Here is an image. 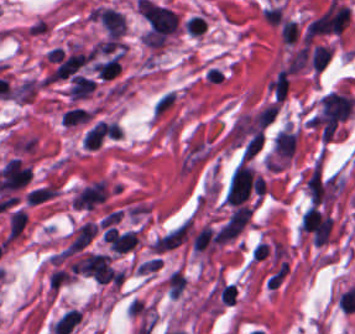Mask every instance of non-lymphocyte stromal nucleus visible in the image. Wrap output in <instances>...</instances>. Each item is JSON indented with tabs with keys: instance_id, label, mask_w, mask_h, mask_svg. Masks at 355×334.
<instances>
[{
	"instance_id": "dd21d789",
	"label": "non-lymphocyte stromal nucleus",
	"mask_w": 355,
	"mask_h": 334,
	"mask_svg": "<svg viewBox=\"0 0 355 334\" xmlns=\"http://www.w3.org/2000/svg\"><path fill=\"white\" fill-rule=\"evenodd\" d=\"M349 12L350 9L334 0L309 22L310 35L340 33L347 23Z\"/></svg>"
},
{
	"instance_id": "a72fc3eb",
	"label": "non-lymphocyte stromal nucleus",
	"mask_w": 355,
	"mask_h": 334,
	"mask_svg": "<svg viewBox=\"0 0 355 334\" xmlns=\"http://www.w3.org/2000/svg\"><path fill=\"white\" fill-rule=\"evenodd\" d=\"M77 271L101 283H117L119 275L104 254L87 253L77 262Z\"/></svg>"
},
{
	"instance_id": "3746e769",
	"label": "non-lymphocyte stromal nucleus",
	"mask_w": 355,
	"mask_h": 334,
	"mask_svg": "<svg viewBox=\"0 0 355 334\" xmlns=\"http://www.w3.org/2000/svg\"><path fill=\"white\" fill-rule=\"evenodd\" d=\"M97 18L107 37L117 39L125 30L124 14L117 10L98 8Z\"/></svg>"
},
{
	"instance_id": "fc2b8d12",
	"label": "non-lymphocyte stromal nucleus",
	"mask_w": 355,
	"mask_h": 334,
	"mask_svg": "<svg viewBox=\"0 0 355 334\" xmlns=\"http://www.w3.org/2000/svg\"><path fill=\"white\" fill-rule=\"evenodd\" d=\"M82 313L79 309H71L57 319L53 331L55 333L68 334L80 319Z\"/></svg>"
},
{
	"instance_id": "81446118",
	"label": "non-lymphocyte stromal nucleus",
	"mask_w": 355,
	"mask_h": 334,
	"mask_svg": "<svg viewBox=\"0 0 355 334\" xmlns=\"http://www.w3.org/2000/svg\"><path fill=\"white\" fill-rule=\"evenodd\" d=\"M169 295L177 296L184 288L186 281L182 274L176 269L169 275L167 281Z\"/></svg>"
}]
</instances>
